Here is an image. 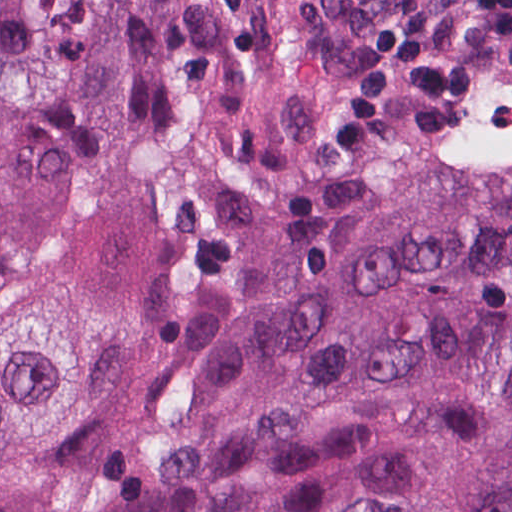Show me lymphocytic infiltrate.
Wrapping results in <instances>:
<instances>
[{
	"mask_svg": "<svg viewBox=\"0 0 512 512\" xmlns=\"http://www.w3.org/2000/svg\"><path fill=\"white\" fill-rule=\"evenodd\" d=\"M512 39V0H393L356 77L330 106V156L368 150L387 100L420 104L411 137H465L459 119L475 70Z\"/></svg>",
	"mask_w": 512,
	"mask_h": 512,
	"instance_id": "lymphocytic-infiltrate-1",
	"label": "lymphocytic infiltrate"
}]
</instances>
